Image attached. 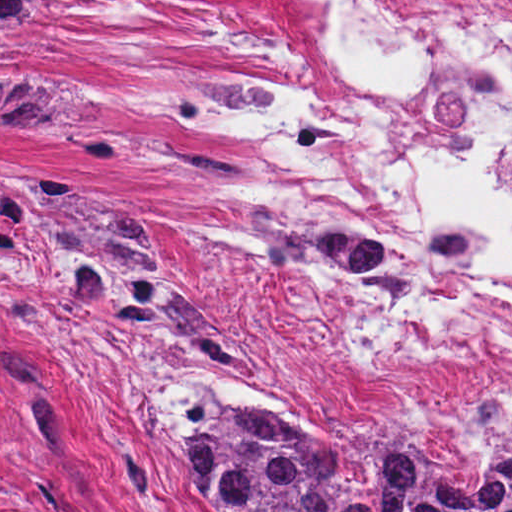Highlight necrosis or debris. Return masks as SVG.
I'll use <instances>...</instances> for the list:
<instances>
[{
	"label": "necrosis or debris",
	"mask_w": 512,
	"mask_h": 512,
	"mask_svg": "<svg viewBox=\"0 0 512 512\" xmlns=\"http://www.w3.org/2000/svg\"><path fill=\"white\" fill-rule=\"evenodd\" d=\"M335 3L273 46L251 98L402 241L407 291L345 300L301 268L270 304L354 395L476 423L512 399V0Z\"/></svg>",
	"instance_id": "4bbe7bcc"
}]
</instances>
